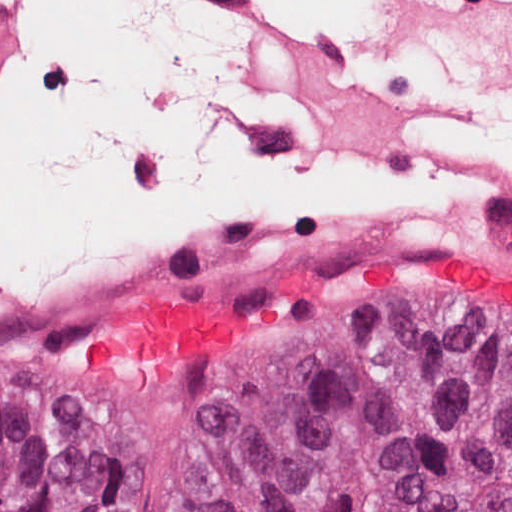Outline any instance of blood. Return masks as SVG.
<instances>
[{"instance_id":"blood-1","label":"blood","mask_w":512,"mask_h":512,"mask_svg":"<svg viewBox=\"0 0 512 512\" xmlns=\"http://www.w3.org/2000/svg\"><path fill=\"white\" fill-rule=\"evenodd\" d=\"M421 254L436 268L460 276L490 309L512 317V274L482 258L443 250ZM237 330L228 315L191 298L150 299L130 313L114 310L103 317L78 347L77 368L86 374L131 366L161 373L233 339Z\"/></svg>"}]
</instances>
